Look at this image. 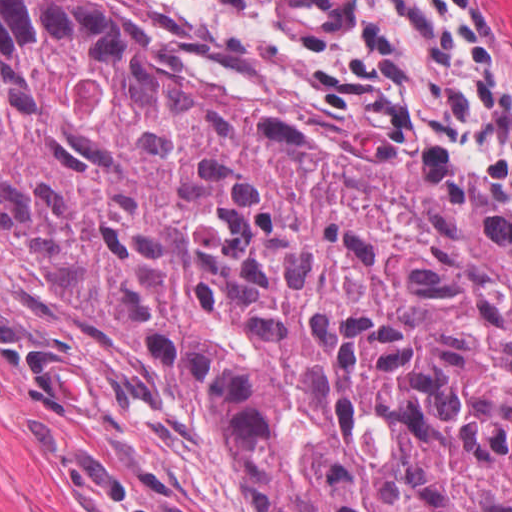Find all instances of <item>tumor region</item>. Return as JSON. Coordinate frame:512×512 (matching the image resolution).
Returning a JSON list of instances; mask_svg holds the SVG:
<instances>
[{
  "label": "tumor region",
  "instance_id": "e687c5a6",
  "mask_svg": "<svg viewBox=\"0 0 512 512\" xmlns=\"http://www.w3.org/2000/svg\"><path fill=\"white\" fill-rule=\"evenodd\" d=\"M0 232L184 368L241 512H512V223L162 0H0Z\"/></svg>",
  "mask_w": 512,
  "mask_h": 512
}]
</instances>
